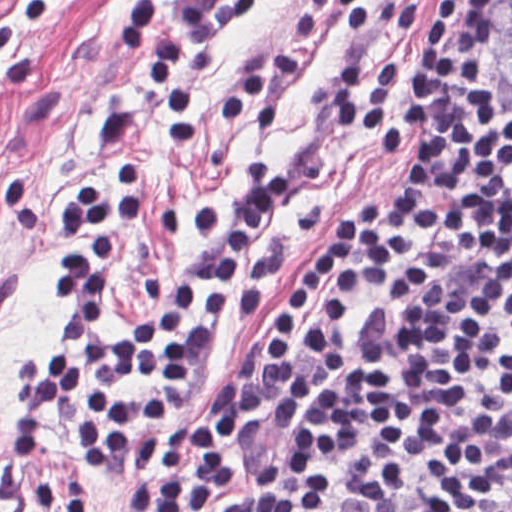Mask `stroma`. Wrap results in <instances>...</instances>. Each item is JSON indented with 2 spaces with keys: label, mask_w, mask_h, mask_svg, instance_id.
<instances>
[{
  "label": "stroma",
  "mask_w": 512,
  "mask_h": 512,
  "mask_svg": "<svg viewBox=\"0 0 512 512\" xmlns=\"http://www.w3.org/2000/svg\"><path fill=\"white\" fill-rule=\"evenodd\" d=\"M167 0L163 39L183 55L194 94V141L173 143L161 127V84L121 44L134 0H57L40 24L16 26L32 54L26 85H0V512H41L32 496L49 481L86 487L102 512H120L130 478L101 471L57 414L49 447L38 461L7 441V424L22 393L28 361L51 348L52 271L62 248L48 226L53 210L76 188L104 174L94 144L102 115L143 113L148 136V208L139 240L115 266L119 301L108 317L117 340L121 321H142L203 253L193 235L214 208L243 192L242 169L253 157L282 164L295 198L271 213L247 246L233 286L231 314L209 340V377L190 397L206 421L235 372L246 331L255 321L234 313L247 292L257 256H271L301 279L343 212L389 187L398 165L379 157L366 133L331 115L329 90L349 63L384 54L404 65V90L414 95L412 55L443 0H262L228 23L212 43H197L178 24ZM11 0H0V21ZM512 0H497L485 46V87L492 113L512 108ZM476 125L471 120L468 127ZM385 308L367 307L355 320V350ZM302 424L267 427L252 454L247 483L217 512H240Z\"/></svg>",
  "instance_id": "stroma-1"
}]
</instances>
